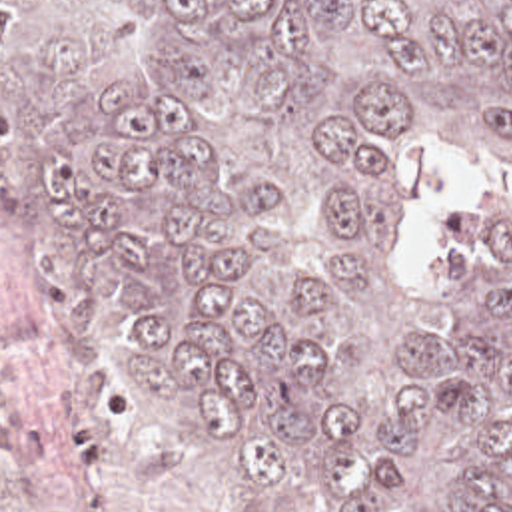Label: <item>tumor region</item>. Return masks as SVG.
Masks as SVG:
<instances>
[{
    "label": "tumor region",
    "mask_w": 512,
    "mask_h": 512,
    "mask_svg": "<svg viewBox=\"0 0 512 512\" xmlns=\"http://www.w3.org/2000/svg\"><path fill=\"white\" fill-rule=\"evenodd\" d=\"M12 229L273 502L512 512V0H0ZM497 153L439 291L411 155Z\"/></svg>",
    "instance_id": "1"
}]
</instances>
